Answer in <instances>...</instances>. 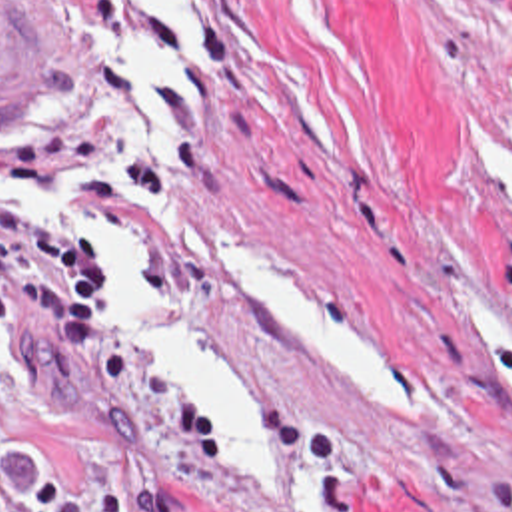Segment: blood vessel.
Returning a JSON list of instances; mask_svg holds the SVG:
<instances>
[{"label": "blood vessel", "instance_id": "8fb6f2fc", "mask_svg": "<svg viewBox=\"0 0 512 512\" xmlns=\"http://www.w3.org/2000/svg\"><path fill=\"white\" fill-rule=\"evenodd\" d=\"M53 100V56L7 2L0 0V124H33Z\"/></svg>", "mask_w": 512, "mask_h": 512}]
</instances>
